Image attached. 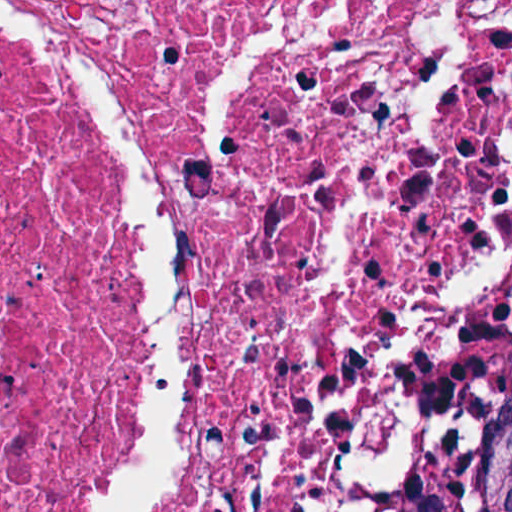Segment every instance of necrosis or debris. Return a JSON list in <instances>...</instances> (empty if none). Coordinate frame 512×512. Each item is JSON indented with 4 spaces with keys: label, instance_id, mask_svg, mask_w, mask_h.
Segmentation results:
<instances>
[{
    "label": "necrosis or debris",
    "instance_id": "necrosis-or-debris-1",
    "mask_svg": "<svg viewBox=\"0 0 512 512\" xmlns=\"http://www.w3.org/2000/svg\"><path fill=\"white\" fill-rule=\"evenodd\" d=\"M512 420V0H0V512H429Z\"/></svg>",
    "mask_w": 512,
    "mask_h": 512
}]
</instances>
